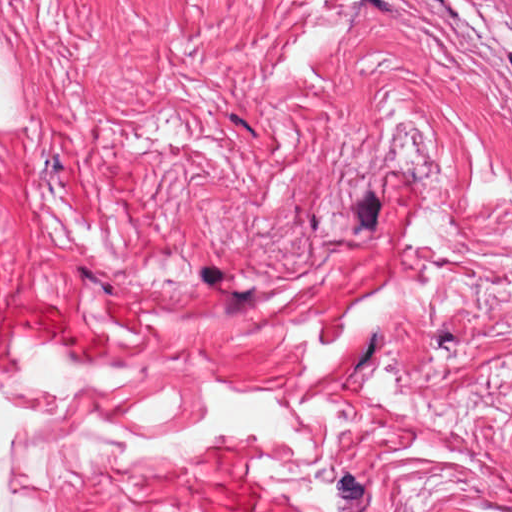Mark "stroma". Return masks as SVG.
I'll use <instances>...</instances> for the list:
<instances>
[{"mask_svg": "<svg viewBox=\"0 0 512 512\" xmlns=\"http://www.w3.org/2000/svg\"><path fill=\"white\" fill-rule=\"evenodd\" d=\"M0 42V297L78 318L0 374L68 420L10 468L52 512H512V16L0 0ZM213 379L275 389L311 460L81 435Z\"/></svg>", "mask_w": 512, "mask_h": 512, "instance_id": "1", "label": "stroma"}]
</instances>
